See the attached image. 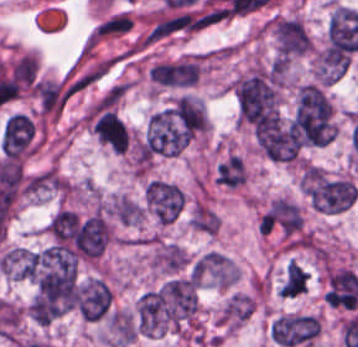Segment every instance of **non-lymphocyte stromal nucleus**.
I'll return each mask as SVG.
<instances>
[{"label": "non-lymphocyte stromal nucleus", "instance_id": "1", "mask_svg": "<svg viewBox=\"0 0 358 347\" xmlns=\"http://www.w3.org/2000/svg\"><path fill=\"white\" fill-rule=\"evenodd\" d=\"M132 24L130 13L125 11L111 13L93 27L92 40L102 41L124 34L131 28Z\"/></svg>", "mask_w": 358, "mask_h": 347}]
</instances>
